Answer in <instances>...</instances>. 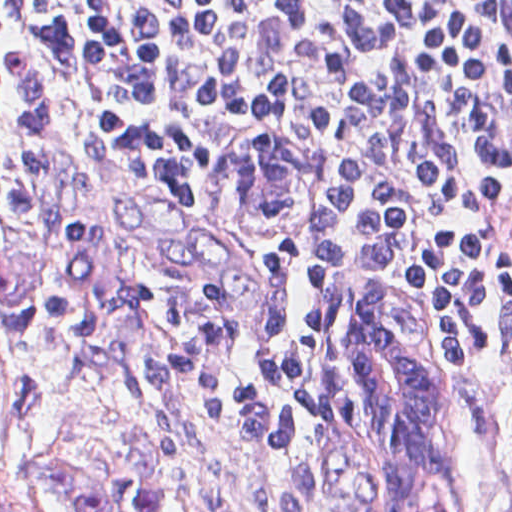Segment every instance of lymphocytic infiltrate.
<instances>
[{"label":"lymphocytic infiltrate","mask_w":512,"mask_h":512,"mask_svg":"<svg viewBox=\"0 0 512 512\" xmlns=\"http://www.w3.org/2000/svg\"><path fill=\"white\" fill-rule=\"evenodd\" d=\"M252 100L353 131L354 171L263 243L250 361L324 399L341 302L384 244L442 333L512 347V0H0V237L23 275L175 384L228 385L204 213Z\"/></svg>","instance_id":"f902f5d3"}]
</instances>
